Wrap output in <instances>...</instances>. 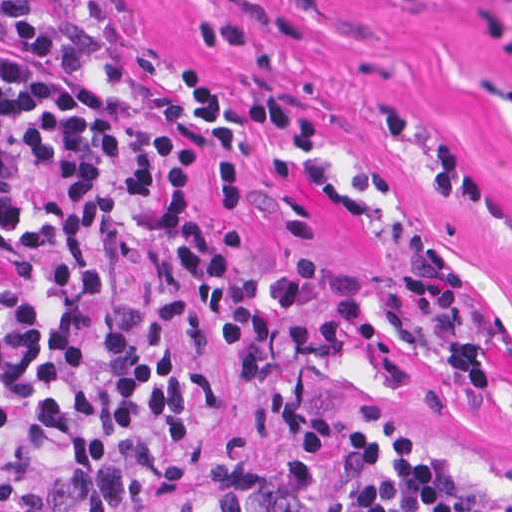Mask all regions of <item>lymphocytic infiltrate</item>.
Masks as SVG:
<instances>
[{
	"label": "lymphocytic infiltrate",
	"mask_w": 512,
	"mask_h": 512,
	"mask_svg": "<svg viewBox=\"0 0 512 512\" xmlns=\"http://www.w3.org/2000/svg\"><path fill=\"white\" fill-rule=\"evenodd\" d=\"M5 44L32 63L0 61V512H311L300 469L272 454L237 458L171 507L152 502V466L198 448L224 425V403L188 353L144 311L109 290L113 236H153L184 210L203 173L204 142L152 127L125 89L73 69L75 57L26 23ZM189 114L208 140L206 191L222 211L245 193L251 132L302 143L320 120L284 90L237 101L204 66L181 65ZM243 232L208 239L174 226L178 295L210 310L317 304L312 320L234 321L213 344L253 409L296 457H404L419 438L364 412L319 415L295 385L301 363L332 362L355 344L400 387L410 364L447 387L487 390L478 341L458 319V280L424 244L400 283L432 346L403 340L371 315L360 281L320 274L302 251L264 281L238 265ZM349 512H512V491L454 458L420 453L363 489Z\"/></svg>",
	"instance_id": "1"
}]
</instances>
